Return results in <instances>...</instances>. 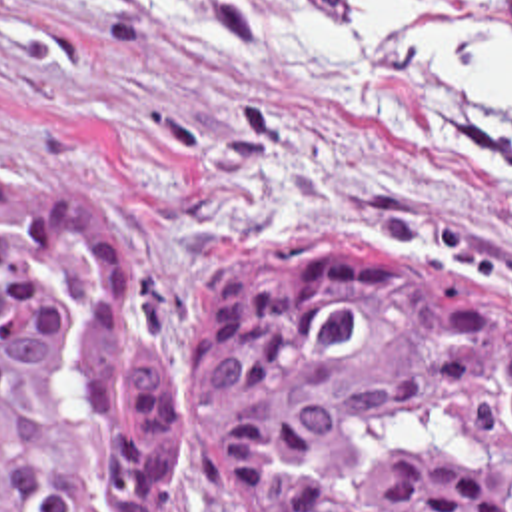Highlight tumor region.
<instances>
[{"mask_svg":"<svg viewBox=\"0 0 512 512\" xmlns=\"http://www.w3.org/2000/svg\"><path fill=\"white\" fill-rule=\"evenodd\" d=\"M512 512V305L352 239L220 275L180 373L86 193L0 179V512Z\"/></svg>","mask_w":512,"mask_h":512,"instance_id":"1","label":"tumor region"}]
</instances>
